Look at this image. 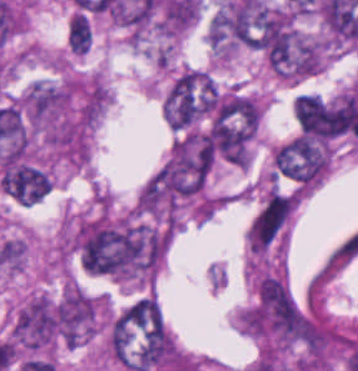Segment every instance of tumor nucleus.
<instances>
[{
  "label": "tumor nucleus",
  "instance_id": "tumor-nucleus-5",
  "mask_svg": "<svg viewBox=\"0 0 358 371\" xmlns=\"http://www.w3.org/2000/svg\"><path fill=\"white\" fill-rule=\"evenodd\" d=\"M92 32L70 50L73 54H86Z\"/></svg>",
  "mask_w": 358,
  "mask_h": 371
},
{
  "label": "tumor nucleus",
  "instance_id": "tumor-nucleus-4",
  "mask_svg": "<svg viewBox=\"0 0 358 371\" xmlns=\"http://www.w3.org/2000/svg\"><path fill=\"white\" fill-rule=\"evenodd\" d=\"M293 113L300 132L314 138L329 140L344 130L338 104L313 94H299Z\"/></svg>",
  "mask_w": 358,
  "mask_h": 371
},
{
  "label": "tumor nucleus",
  "instance_id": "tumor-nucleus-3",
  "mask_svg": "<svg viewBox=\"0 0 358 371\" xmlns=\"http://www.w3.org/2000/svg\"><path fill=\"white\" fill-rule=\"evenodd\" d=\"M274 165L281 175L304 184H313L327 169L329 152L319 143L296 135L274 147Z\"/></svg>",
  "mask_w": 358,
  "mask_h": 371
},
{
  "label": "tumor nucleus",
  "instance_id": "tumor-nucleus-1",
  "mask_svg": "<svg viewBox=\"0 0 358 371\" xmlns=\"http://www.w3.org/2000/svg\"><path fill=\"white\" fill-rule=\"evenodd\" d=\"M59 337V298L34 292L13 307L8 338L25 351L49 348Z\"/></svg>",
  "mask_w": 358,
  "mask_h": 371
},
{
  "label": "tumor nucleus",
  "instance_id": "tumor-nucleus-2",
  "mask_svg": "<svg viewBox=\"0 0 358 371\" xmlns=\"http://www.w3.org/2000/svg\"><path fill=\"white\" fill-rule=\"evenodd\" d=\"M101 298L68 283L56 302L58 334L65 346L76 347L99 331Z\"/></svg>",
  "mask_w": 358,
  "mask_h": 371
},
{
  "label": "tumor nucleus",
  "instance_id": "tumor-nucleus-6",
  "mask_svg": "<svg viewBox=\"0 0 358 371\" xmlns=\"http://www.w3.org/2000/svg\"><path fill=\"white\" fill-rule=\"evenodd\" d=\"M137 298L143 301L145 304H147L149 307H151L152 309H154L156 312L160 314L159 307L157 305L156 300L149 298L145 295L141 297H137Z\"/></svg>",
  "mask_w": 358,
  "mask_h": 371
}]
</instances>
